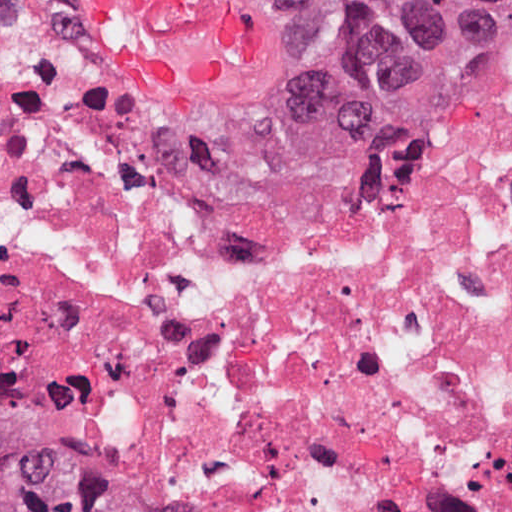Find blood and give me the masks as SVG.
Masks as SVG:
<instances>
[{
    "mask_svg": "<svg viewBox=\"0 0 512 512\" xmlns=\"http://www.w3.org/2000/svg\"><path fill=\"white\" fill-rule=\"evenodd\" d=\"M110 61L161 97L230 83L265 51V16L236 0H83Z\"/></svg>",
    "mask_w": 512,
    "mask_h": 512,
    "instance_id": "blood-1",
    "label": "blood"
}]
</instances>
